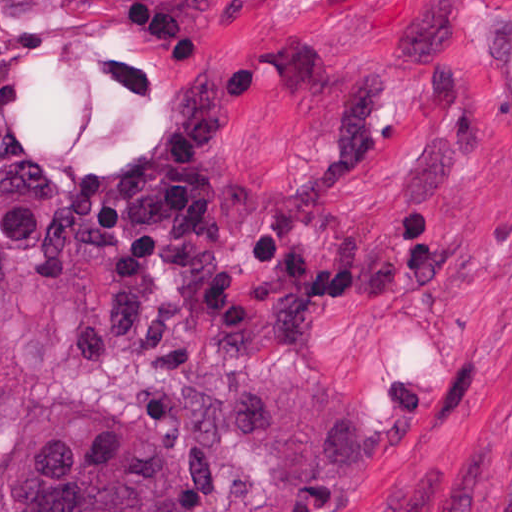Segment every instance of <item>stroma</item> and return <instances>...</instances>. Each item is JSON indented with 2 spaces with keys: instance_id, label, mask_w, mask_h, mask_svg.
Listing matches in <instances>:
<instances>
[{
  "instance_id": "obj_1",
  "label": "stroma",
  "mask_w": 512,
  "mask_h": 512,
  "mask_svg": "<svg viewBox=\"0 0 512 512\" xmlns=\"http://www.w3.org/2000/svg\"><path fill=\"white\" fill-rule=\"evenodd\" d=\"M506 0H0V161L136 228L135 331L39 395L185 512H512Z\"/></svg>"
}]
</instances>
